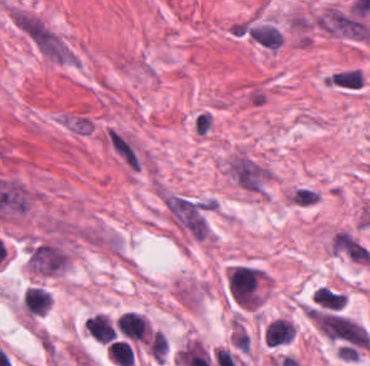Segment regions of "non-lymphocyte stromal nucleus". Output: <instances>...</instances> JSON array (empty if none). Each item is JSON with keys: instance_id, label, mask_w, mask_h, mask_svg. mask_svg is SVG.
Segmentation results:
<instances>
[{"instance_id": "obj_5", "label": "non-lymphocyte stromal nucleus", "mask_w": 370, "mask_h": 366, "mask_svg": "<svg viewBox=\"0 0 370 366\" xmlns=\"http://www.w3.org/2000/svg\"><path fill=\"white\" fill-rule=\"evenodd\" d=\"M28 263L34 273L56 275L66 269V255L59 245L39 243L30 249Z\"/></svg>"}, {"instance_id": "obj_6", "label": "non-lymphocyte stromal nucleus", "mask_w": 370, "mask_h": 366, "mask_svg": "<svg viewBox=\"0 0 370 366\" xmlns=\"http://www.w3.org/2000/svg\"><path fill=\"white\" fill-rule=\"evenodd\" d=\"M57 122L70 134L87 135L94 128L95 120L88 109L64 108L57 113Z\"/></svg>"}, {"instance_id": "obj_9", "label": "non-lymphocyte stromal nucleus", "mask_w": 370, "mask_h": 366, "mask_svg": "<svg viewBox=\"0 0 370 366\" xmlns=\"http://www.w3.org/2000/svg\"><path fill=\"white\" fill-rule=\"evenodd\" d=\"M118 332L134 342H145L148 322L136 312H123L117 318Z\"/></svg>"}, {"instance_id": "obj_7", "label": "non-lymphocyte stromal nucleus", "mask_w": 370, "mask_h": 366, "mask_svg": "<svg viewBox=\"0 0 370 366\" xmlns=\"http://www.w3.org/2000/svg\"><path fill=\"white\" fill-rule=\"evenodd\" d=\"M366 76L357 66H343L325 75V85L340 90H359Z\"/></svg>"}, {"instance_id": "obj_3", "label": "non-lymphocyte stromal nucleus", "mask_w": 370, "mask_h": 366, "mask_svg": "<svg viewBox=\"0 0 370 366\" xmlns=\"http://www.w3.org/2000/svg\"><path fill=\"white\" fill-rule=\"evenodd\" d=\"M318 329L344 354L368 349L367 331L343 315L316 314Z\"/></svg>"}, {"instance_id": "obj_1", "label": "non-lymphocyte stromal nucleus", "mask_w": 370, "mask_h": 366, "mask_svg": "<svg viewBox=\"0 0 370 366\" xmlns=\"http://www.w3.org/2000/svg\"><path fill=\"white\" fill-rule=\"evenodd\" d=\"M222 166L240 191L258 198H266L277 176L268 163L242 148L224 159Z\"/></svg>"}, {"instance_id": "obj_4", "label": "non-lymphocyte stromal nucleus", "mask_w": 370, "mask_h": 366, "mask_svg": "<svg viewBox=\"0 0 370 366\" xmlns=\"http://www.w3.org/2000/svg\"><path fill=\"white\" fill-rule=\"evenodd\" d=\"M236 36L266 50H279L286 38V32L269 16L249 15L232 24Z\"/></svg>"}, {"instance_id": "obj_10", "label": "non-lymphocyte stromal nucleus", "mask_w": 370, "mask_h": 366, "mask_svg": "<svg viewBox=\"0 0 370 366\" xmlns=\"http://www.w3.org/2000/svg\"><path fill=\"white\" fill-rule=\"evenodd\" d=\"M345 295L333 287L321 285L312 294L311 306L325 310H338L343 308Z\"/></svg>"}, {"instance_id": "obj_8", "label": "non-lymphocyte stromal nucleus", "mask_w": 370, "mask_h": 366, "mask_svg": "<svg viewBox=\"0 0 370 366\" xmlns=\"http://www.w3.org/2000/svg\"><path fill=\"white\" fill-rule=\"evenodd\" d=\"M331 246L344 257L360 263H369L367 248L347 232L339 231L332 237Z\"/></svg>"}, {"instance_id": "obj_2", "label": "non-lymphocyte stromal nucleus", "mask_w": 370, "mask_h": 366, "mask_svg": "<svg viewBox=\"0 0 370 366\" xmlns=\"http://www.w3.org/2000/svg\"><path fill=\"white\" fill-rule=\"evenodd\" d=\"M157 194L172 227L187 241L208 244L213 235L209 215L158 186Z\"/></svg>"}]
</instances>
